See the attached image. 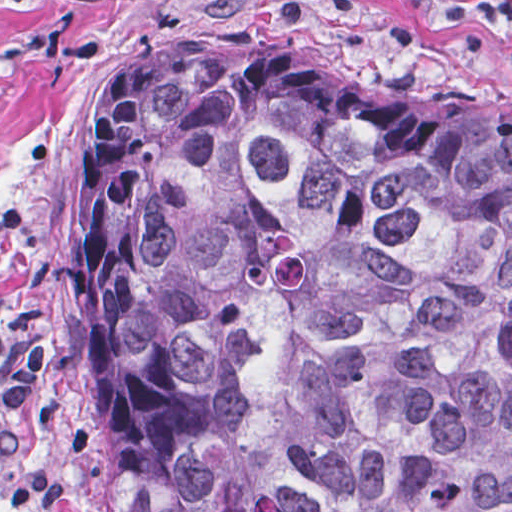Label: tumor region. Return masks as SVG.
Wrapping results in <instances>:
<instances>
[{"label":"tumor region","instance_id":"obj_1","mask_svg":"<svg viewBox=\"0 0 512 512\" xmlns=\"http://www.w3.org/2000/svg\"><path fill=\"white\" fill-rule=\"evenodd\" d=\"M81 215L117 512H512V120L199 29L106 82Z\"/></svg>","mask_w":512,"mask_h":512}]
</instances>
